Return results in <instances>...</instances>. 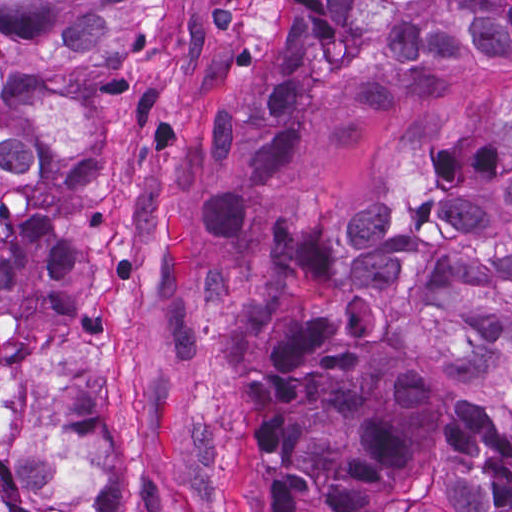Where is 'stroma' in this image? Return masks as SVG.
<instances>
[{
    "instance_id": "obj_1",
    "label": "stroma",
    "mask_w": 512,
    "mask_h": 512,
    "mask_svg": "<svg viewBox=\"0 0 512 512\" xmlns=\"http://www.w3.org/2000/svg\"><path fill=\"white\" fill-rule=\"evenodd\" d=\"M147 1L115 65V185L81 262L98 324L71 345L91 423L121 446L126 512H233V394L268 355L267 238L293 221H346L401 188L414 153L463 132L512 62L466 61L426 113L379 119L348 148L313 130L305 159L236 233L199 228L213 179L210 108L258 61L283 1Z\"/></svg>"
}]
</instances>
